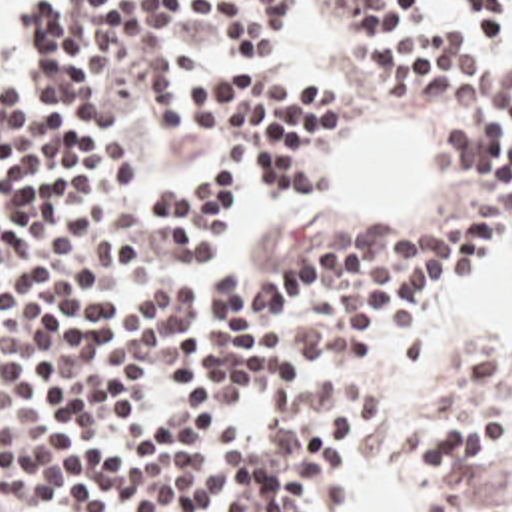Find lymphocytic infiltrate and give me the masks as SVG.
<instances>
[{"label":"lymphocytic infiltrate","mask_w":512,"mask_h":512,"mask_svg":"<svg viewBox=\"0 0 512 512\" xmlns=\"http://www.w3.org/2000/svg\"><path fill=\"white\" fill-rule=\"evenodd\" d=\"M347 86H427L481 224L309 216L233 282L235 178L317 194L337 98L275 76L273 0H0V512H337L383 406L319 356L417 326L512 238V68L413 0H329ZM487 42L512 0H457ZM287 40V0H285ZM247 270V268H235ZM427 512H512V354L419 418Z\"/></svg>","instance_id":"f902f5d3"}]
</instances>
